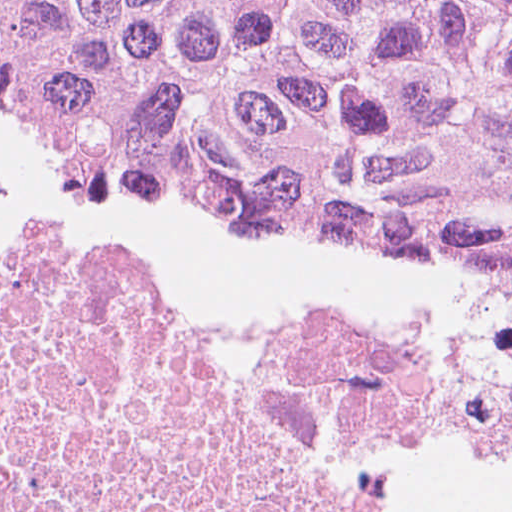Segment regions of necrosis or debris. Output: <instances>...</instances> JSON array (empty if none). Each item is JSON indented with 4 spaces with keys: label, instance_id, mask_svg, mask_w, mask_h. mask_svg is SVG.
I'll list each match as a JSON object with an SVG mask.
<instances>
[{
    "label": "necrosis or debris",
    "instance_id": "necrosis-or-debris-1",
    "mask_svg": "<svg viewBox=\"0 0 512 512\" xmlns=\"http://www.w3.org/2000/svg\"><path fill=\"white\" fill-rule=\"evenodd\" d=\"M0 512H512V253L224 324L0 182Z\"/></svg>",
    "mask_w": 512,
    "mask_h": 512
}]
</instances>
